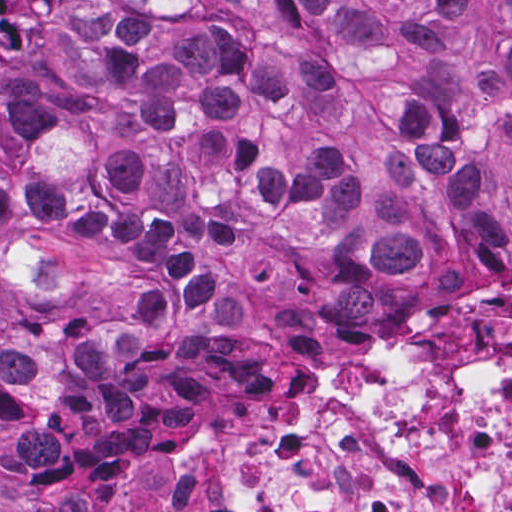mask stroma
<instances>
[{
  "label": "stroma",
  "mask_w": 512,
  "mask_h": 512,
  "mask_svg": "<svg viewBox=\"0 0 512 512\" xmlns=\"http://www.w3.org/2000/svg\"><path fill=\"white\" fill-rule=\"evenodd\" d=\"M24 153L25 141L0 126V183L24 164ZM499 296L512 297V272L506 282L462 287L433 314L390 326L343 324L325 316L294 322L293 297V338L269 384L220 422L160 445L99 495L92 512H226L194 491L175 490L164 477L223 424L274 416L286 405L303 406L309 389L339 373L362 346L381 347L429 333Z\"/></svg>",
  "instance_id": "obj_1"
}]
</instances>
